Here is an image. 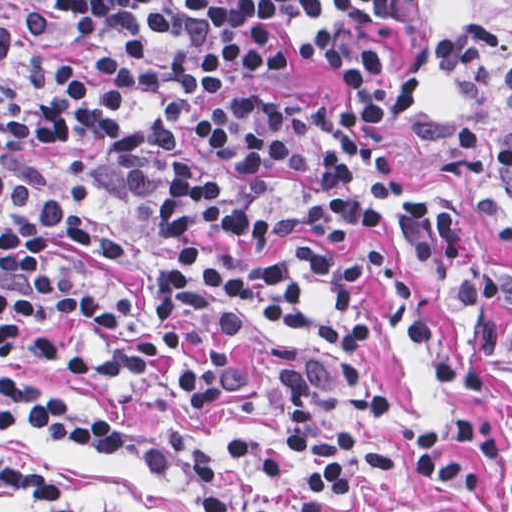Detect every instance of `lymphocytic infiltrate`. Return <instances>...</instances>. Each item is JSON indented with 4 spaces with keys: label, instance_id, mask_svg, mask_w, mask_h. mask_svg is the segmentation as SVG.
Returning <instances> with one entry per match:
<instances>
[{
    "label": "lymphocytic infiltrate",
    "instance_id": "f902f5d3",
    "mask_svg": "<svg viewBox=\"0 0 512 512\" xmlns=\"http://www.w3.org/2000/svg\"><path fill=\"white\" fill-rule=\"evenodd\" d=\"M341 67L348 95L333 116L302 96L234 93L198 121L194 144L237 173L230 192L196 163L178 162L159 208L166 240L207 232L219 258L183 246L176 266L150 277L156 323L138 343L108 352L98 369L168 391L194 409L231 403L246 381L238 331L258 313L301 327L304 298L285 267L255 256L281 238L367 228L403 241L457 294L470 333L512 363V274L475 264L446 203L396 195L379 124L411 123L425 100L413 48V0H1V345L37 320L65 314L110 328L132 299L108 303L72 287L53 261L61 248L120 254L124 247L89 221L87 208L119 191L91 186L86 163L62 158L60 182L31 165L43 144L78 145L104 134L135 192L163 184L164 165L186 123L208 97L242 77H269L282 47ZM443 68L457 95L493 93L512 109V43L469 17L451 21ZM480 152L512 196V140L460 121L435 141ZM332 302L315 330L326 354L286 343L266 348L261 368L283 393L285 462L358 492L361 479L418 478L471 494L486 477L469 452L500 469L512 492V435L492 426L477 369L435 327L421 295L383 252L361 246L343 259L295 249ZM424 351L464 413L424 414L409 443L367 442L373 362L382 315ZM30 352L53 358L37 339ZM66 362L87 367L71 356ZM29 425L80 446H113L164 475L184 472L196 512H324L286 505L231 484L175 433L59 394L1 383V426ZM1 512H123L78 506L36 469L1 448Z\"/></svg>",
    "mask_w": 512,
    "mask_h": 512
}]
</instances>
